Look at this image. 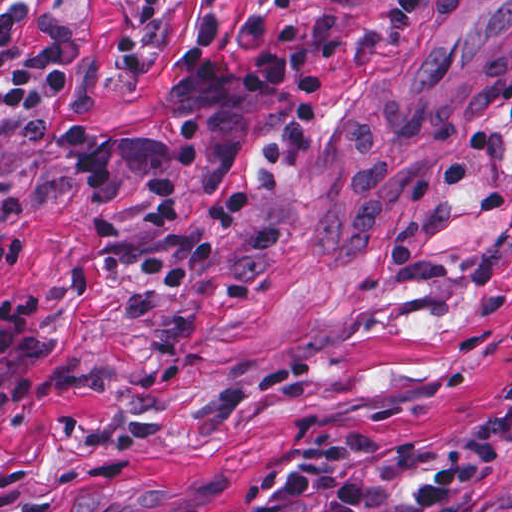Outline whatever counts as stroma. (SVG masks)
Masks as SVG:
<instances>
[{
    "label": "stroma",
    "mask_w": 512,
    "mask_h": 512,
    "mask_svg": "<svg viewBox=\"0 0 512 512\" xmlns=\"http://www.w3.org/2000/svg\"><path fill=\"white\" fill-rule=\"evenodd\" d=\"M301 0L342 23L320 114L286 168L259 152L255 96L204 90L201 16L242 77L275 0H0V294L43 289L52 348L30 402L0 410V512L276 509L277 472L353 436L368 478L417 491L494 423L471 492L512 485V0ZM61 62L64 113L107 133L91 184L46 125L11 111L16 75ZM174 179L211 232L247 204L182 291L139 269L166 246L149 179ZM0 354V383L17 365Z\"/></svg>",
    "instance_id": "stroma-1"
}]
</instances>
